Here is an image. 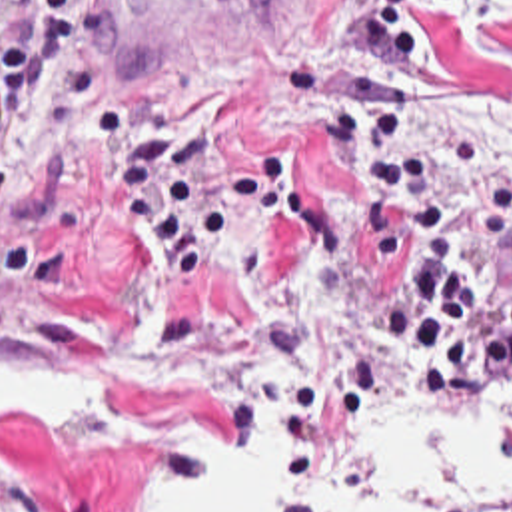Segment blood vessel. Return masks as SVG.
I'll use <instances>...</instances> for the list:
<instances>
[{
  "mask_svg": "<svg viewBox=\"0 0 512 512\" xmlns=\"http://www.w3.org/2000/svg\"><path fill=\"white\" fill-rule=\"evenodd\" d=\"M265 0H82L78 91L125 69L179 55L251 17Z\"/></svg>",
  "mask_w": 512,
  "mask_h": 512,
  "instance_id": "1",
  "label": "blood vessel"
}]
</instances>
